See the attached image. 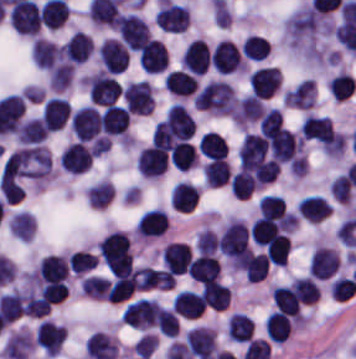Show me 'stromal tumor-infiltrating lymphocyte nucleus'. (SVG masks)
<instances>
[{
  "label": "stromal tumor-infiltrating lymphocyte nucleus",
  "instance_id": "f3e2335f",
  "mask_svg": "<svg viewBox=\"0 0 356 359\" xmlns=\"http://www.w3.org/2000/svg\"><path fill=\"white\" fill-rule=\"evenodd\" d=\"M282 101L290 107L311 108L316 103V85L312 77H305L282 93Z\"/></svg>",
  "mask_w": 356,
  "mask_h": 359
},
{
  "label": "stromal tumor-infiltrating lymphocyte nucleus",
  "instance_id": "abfb95fc",
  "mask_svg": "<svg viewBox=\"0 0 356 359\" xmlns=\"http://www.w3.org/2000/svg\"><path fill=\"white\" fill-rule=\"evenodd\" d=\"M128 110L117 102H110L100 115L101 130L107 134L126 136L128 133Z\"/></svg>",
  "mask_w": 356,
  "mask_h": 359
},
{
  "label": "stromal tumor-infiltrating lymphocyte nucleus",
  "instance_id": "52c7bb5b",
  "mask_svg": "<svg viewBox=\"0 0 356 359\" xmlns=\"http://www.w3.org/2000/svg\"><path fill=\"white\" fill-rule=\"evenodd\" d=\"M118 35L128 51H138L148 37L146 20L133 13H120L115 24Z\"/></svg>",
  "mask_w": 356,
  "mask_h": 359
},
{
  "label": "stromal tumor-infiltrating lymphocyte nucleus",
  "instance_id": "4245b91a",
  "mask_svg": "<svg viewBox=\"0 0 356 359\" xmlns=\"http://www.w3.org/2000/svg\"><path fill=\"white\" fill-rule=\"evenodd\" d=\"M300 132L301 138L319 143L333 132V127L329 116L309 113L301 122Z\"/></svg>",
  "mask_w": 356,
  "mask_h": 359
},
{
  "label": "stromal tumor-infiltrating lymphocyte nucleus",
  "instance_id": "4c9ddf68",
  "mask_svg": "<svg viewBox=\"0 0 356 359\" xmlns=\"http://www.w3.org/2000/svg\"><path fill=\"white\" fill-rule=\"evenodd\" d=\"M39 116H31L19 123L15 136L19 144H35L48 134Z\"/></svg>",
  "mask_w": 356,
  "mask_h": 359
},
{
  "label": "stromal tumor-infiltrating lymphocyte nucleus",
  "instance_id": "2761f720",
  "mask_svg": "<svg viewBox=\"0 0 356 359\" xmlns=\"http://www.w3.org/2000/svg\"><path fill=\"white\" fill-rule=\"evenodd\" d=\"M200 296L205 306L213 309H224L230 301V290L220 281L209 280L204 285Z\"/></svg>",
  "mask_w": 356,
  "mask_h": 359
},
{
  "label": "stromal tumor-infiltrating lymphocyte nucleus",
  "instance_id": "3290ff9b",
  "mask_svg": "<svg viewBox=\"0 0 356 359\" xmlns=\"http://www.w3.org/2000/svg\"><path fill=\"white\" fill-rule=\"evenodd\" d=\"M189 20L190 15L187 5L159 0L154 13V21L160 28L166 31L180 32Z\"/></svg>",
  "mask_w": 356,
  "mask_h": 359
},
{
  "label": "stromal tumor-infiltrating lymphocyte nucleus",
  "instance_id": "4f13568d",
  "mask_svg": "<svg viewBox=\"0 0 356 359\" xmlns=\"http://www.w3.org/2000/svg\"><path fill=\"white\" fill-rule=\"evenodd\" d=\"M168 230V214L158 208L146 209L136 222L135 235L151 238Z\"/></svg>",
  "mask_w": 356,
  "mask_h": 359
},
{
  "label": "stromal tumor-infiltrating lymphocyte nucleus",
  "instance_id": "4803ca6d",
  "mask_svg": "<svg viewBox=\"0 0 356 359\" xmlns=\"http://www.w3.org/2000/svg\"><path fill=\"white\" fill-rule=\"evenodd\" d=\"M70 114V105L64 97L51 96L41 111V121L52 131L63 127Z\"/></svg>",
  "mask_w": 356,
  "mask_h": 359
},
{
  "label": "stromal tumor-infiltrating lymphocyte nucleus",
  "instance_id": "9ea309e8",
  "mask_svg": "<svg viewBox=\"0 0 356 359\" xmlns=\"http://www.w3.org/2000/svg\"><path fill=\"white\" fill-rule=\"evenodd\" d=\"M61 167L70 173H83L90 168L91 150L78 141H71L62 151L60 157Z\"/></svg>",
  "mask_w": 356,
  "mask_h": 359
},
{
  "label": "stromal tumor-infiltrating lymphocyte nucleus",
  "instance_id": "2a367800",
  "mask_svg": "<svg viewBox=\"0 0 356 359\" xmlns=\"http://www.w3.org/2000/svg\"><path fill=\"white\" fill-rule=\"evenodd\" d=\"M264 112L263 100L254 92H246L236 103L232 117L238 126L257 121Z\"/></svg>",
  "mask_w": 356,
  "mask_h": 359
},
{
  "label": "stromal tumor-infiltrating lymphocyte nucleus",
  "instance_id": "42bb06b2",
  "mask_svg": "<svg viewBox=\"0 0 356 359\" xmlns=\"http://www.w3.org/2000/svg\"><path fill=\"white\" fill-rule=\"evenodd\" d=\"M264 328L269 340L282 343L291 332V321L283 313L273 310L267 317Z\"/></svg>",
  "mask_w": 356,
  "mask_h": 359
},
{
  "label": "stromal tumor-infiltrating lymphocyte nucleus",
  "instance_id": "9e4306bb",
  "mask_svg": "<svg viewBox=\"0 0 356 359\" xmlns=\"http://www.w3.org/2000/svg\"><path fill=\"white\" fill-rule=\"evenodd\" d=\"M356 89V80L352 74L347 71H340L333 75L328 82V93L340 100L349 98Z\"/></svg>",
  "mask_w": 356,
  "mask_h": 359
},
{
  "label": "stromal tumor-infiltrating lymphocyte nucleus",
  "instance_id": "bc302bb0",
  "mask_svg": "<svg viewBox=\"0 0 356 359\" xmlns=\"http://www.w3.org/2000/svg\"><path fill=\"white\" fill-rule=\"evenodd\" d=\"M237 95L224 80H210L193 95L194 107L215 114H231Z\"/></svg>",
  "mask_w": 356,
  "mask_h": 359
},
{
  "label": "stromal tumor-infiltrating lymphocyte nucleus",
  "instance_id": "3c572f05",
  "mask_svg": "<svg viewBox=\"0 0 356 359\" xmlns=\"http://www.w3.org/2000/svg\"><path fill=\"white\" fill-rule=\"evenodd\" d=\"M291 251V241L283 233H276L269 241L265 256L273 265L284 266L287 263Z\"/></svg>",
  "mask_w": 356,
  "mask_h": 359
}]
</instances>
